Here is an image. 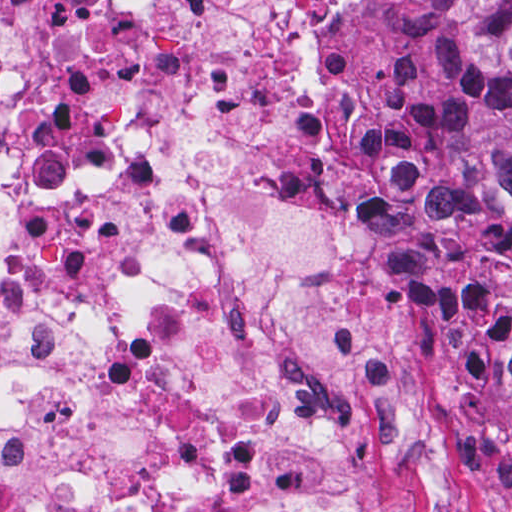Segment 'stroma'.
<instances>
[{
    "label": "stroma",
    "instance_id": "obj_1",
    "mask_svg": "<svg viewBox=\"0 0 512 512\" xmlns=\"http://www.w3.org/2000/svg\"><path fill=\"white\" fill-rule=\"evenodd\" d=\"M440 12L457 59V35L446 0H432ZM314 54L309 41V55ZM470 512H512V411L502 395V426L487 477V503Z\"/></svg>",
    "mask_w": 512,
    "mask_h": 512
}]
</instances>
